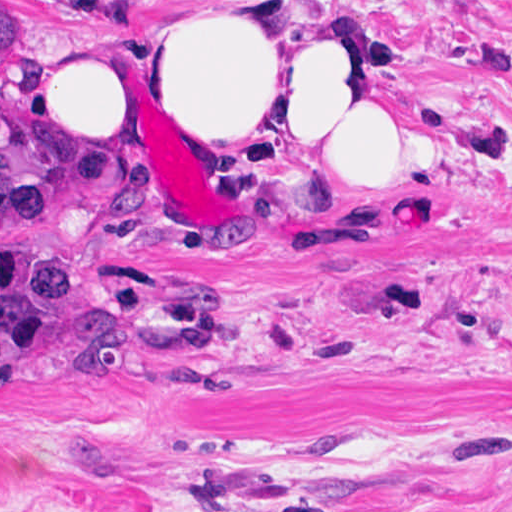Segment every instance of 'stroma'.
<instances>
[{
    "instance_id": "stroma-1",
    "label": "stroma",
    "mask_w": 512,
    "mask_h": 512,
    "mask_svg": "<svg viewBox=\"0 0 512 512\" xmlns=\"http://www.w3.org/2000/svg\"><path fill=\"white\" fill-rule=\"evenodd\" d=\"M172 1L28 0L38 46L0 54V89L41 105L52 66ZM277 6L470 162L294 169L312 136L184 110L60 226L0 235L145 324L134 382L0 380V512H512V0Z\"/></svg>"
}]
</instances>
